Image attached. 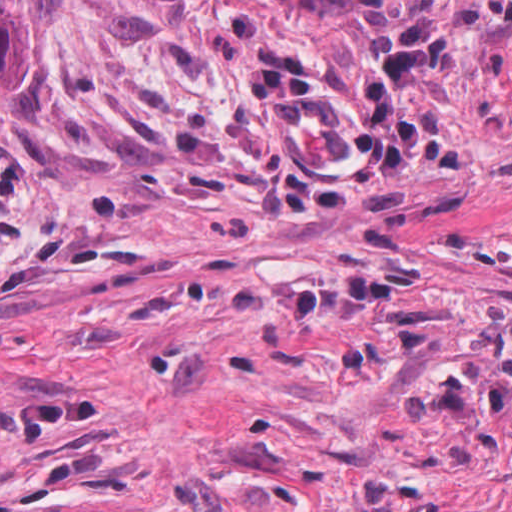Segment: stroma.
<instances>
[{
	"label": "stroma",
	"instance_id": "1",
	"mask_svg": "<svg viewBox=\"0 0 512 512\" xmlns=\"http://www.w3.org/2000/svg\"><path fill=\"white\" fill-rule=\"evenodd\" d=\"M0 512H512V162L1 457Z\"/></svg>",
	"mask_w": 512,
	"mask_h": 512
}]
</instances>
